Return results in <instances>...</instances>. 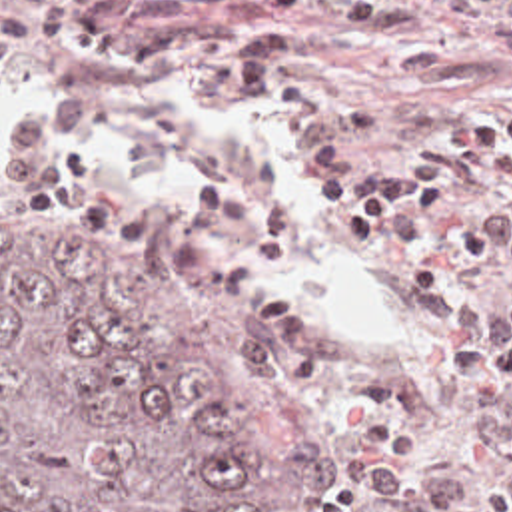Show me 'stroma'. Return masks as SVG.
<instances>
[{
	"label": "stroma",
	"mask_w": 512,
	"mask_h": 512,
	"mask_svg": "<svg viewBox=\"0 0 512 512\" xmlns=\"http://www.w3.org/2000/svg\"><path fill=\"white\" fill-rule=\"evenodd\" d=\"M413 6L411 30L373 36L345 16L287 14L253 0L208 6L164 30L214 28L226 50L182 70H118L70 52L0 56V68L36 86L84 82L114 96L140 86L214 82L226 78L243 50L273 26L303 30L323 42L341 102L335 126L355 130L365 152H433L477 108L512 106V0H399ZM329 130L281 116L271 102H239L212 116L172 146L130 128L90 132L80 154L108 180L152 206L148 226H98L38 208H0V238L42 234H114L166 254L190 297L231 339L247 349L277 383L317 465L325 473V512L353 501L351 463L317 405L279 377L253 341L241 309L194 263V214L204 190L243 176L287 202L313 244V307L343 339H367L383 319L329 238L307 178V152Z\"/></svg>",
	"instance_id": "stroma-1"
}]
</instances>
